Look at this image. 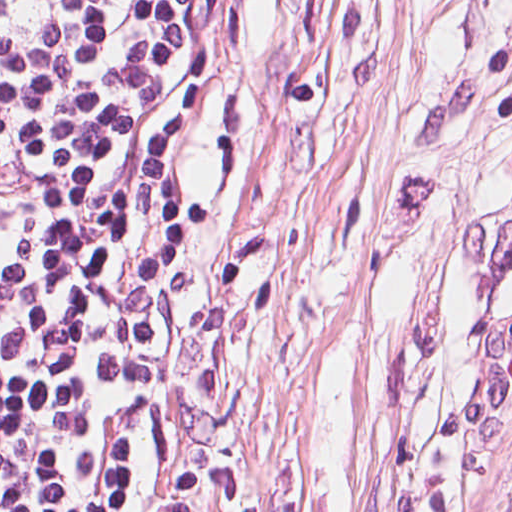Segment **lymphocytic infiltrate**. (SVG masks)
<instances>
[{
    "instance_id": "obj_1",
    "label": "lymphocytic infiltrate",
    "mask_w": 512,
    "mask_h": 512,
    "mask_svg": "<svg viewBox=\"0 0 512 512\" xmlns=\"http://www.w3.org/2000/svg\"><path fill=\"white\" fill-rule=\"evenodd\" d=\"M225 0H0V512H168L172 145Z\"/></svg>"
}]
</instances>
